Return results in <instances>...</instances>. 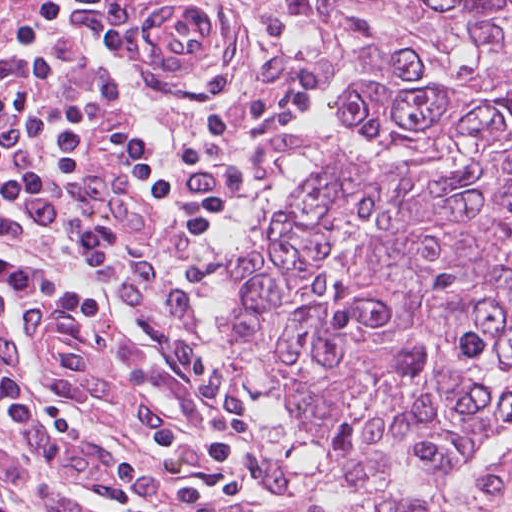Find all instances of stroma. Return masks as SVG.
I'll return each mask as SVG.
<instances>
[{
	"mask_svg": "<svg viewBox=\"0 0 512 512\" xmlns=\"http://www.w3.org/2000/svg\"><path fill=\"white\" fill-rule=\"evenodd\" d=\"M348 125L281 0H0V512H266L233 260Z\"/></svg>",
	"mask_w": 512,
	"mask_h": 512,
	"instance_id": "35a3bbf8",
	"label": "stroma"
}]
</instances>
